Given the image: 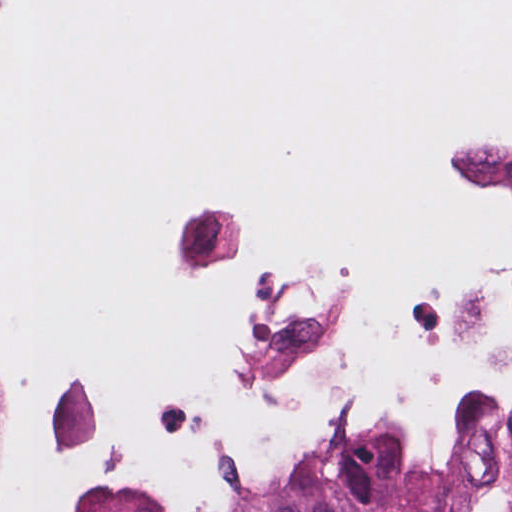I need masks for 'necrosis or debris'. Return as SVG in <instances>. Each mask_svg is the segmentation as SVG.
<instances>
[{"instance_id":"4bbe7bcc","label":"necrosis or debris","mask_w":512,"mask_h":512,"mask_svg":"<svg viewBox=\"0 0 512 512\" xmlns=\"http://www.w3.org/2000/svg\"><path fill=\"white\" fill-rule=\"evenodd\" d=\"M372 208L210 177L163 193L132 273L186 309V386L73 373L0 425V512H212L314 460L422 464L457 400L512 393V84L405 141Z\"/></svg>"}]
</instances>
